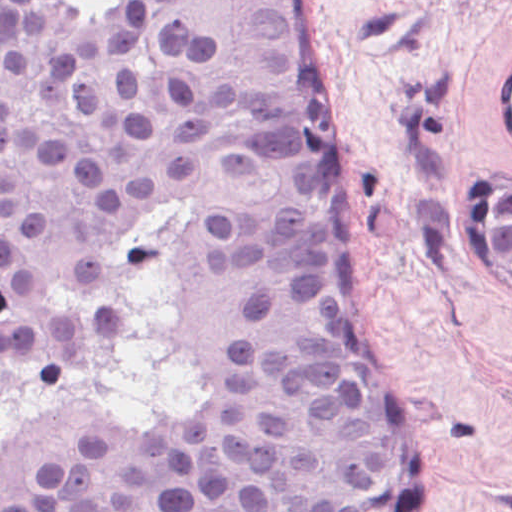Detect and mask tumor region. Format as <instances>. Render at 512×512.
I'll use <instances>...</instances> for the list:
<instances>
[{
  "label": "tumor region",
  "instance_id": "obj_1",
  "mask_svg": "<svg viewBox=\"0 0 512 512\" xmlns=\"http://www.w3.org/2000/svg\"><path fill=\"white\" fill-rule=\"evenodd\" d=\"M485 249L512 292V183L497 171L485 189Z\"/></svg>",
  "mask_w": 512,
  "mask_h": 512
}]
</instances>
